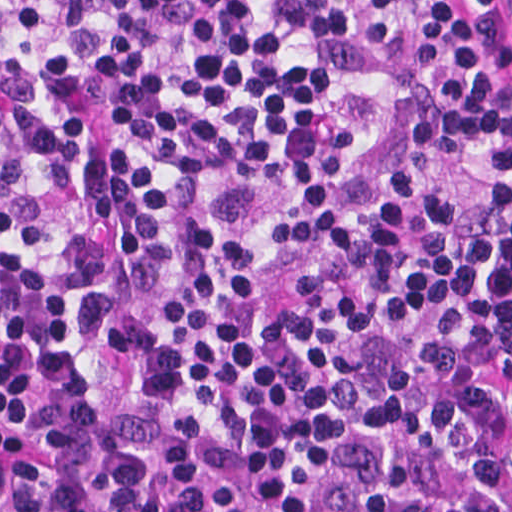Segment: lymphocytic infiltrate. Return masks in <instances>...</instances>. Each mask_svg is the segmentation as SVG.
Instances as JSON below:
<instances>
[{
    "instance_id": "obj_1",
    "label": "lymphocytic infiltrate",
    "mask_w": 512,
    "mask_h": 512,
    "mask_svg": "<svg viewBox=\"0 0 512 512\" xmlns=\"http://www.w3.org/2000/svg\"><path fill=\"white\" fill-rule=\"evenodd\" d=\"M504 248L490 15L0 0V404L40 512H512Z\"/></svg>"
}]
</instances>
